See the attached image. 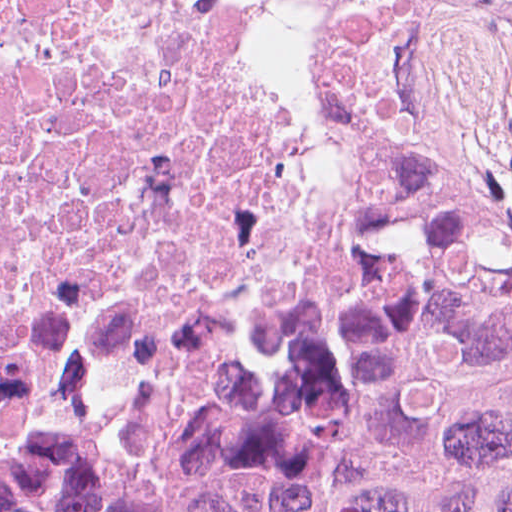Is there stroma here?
<instances>
[{
	"label": "stroma",
	"instance_id": "35a3bbf8",
	"mask_svg": "<svg viewBox=\"0 0 512 512\" xmlns=\"http://www.w3.org/2000/svg\"><path fill=\"white\" fill-rule=\"evenodd\" d=\"M363 202L364 197L361 194V212ZM350 251L339 268L337 280L342 274ZM27 474L39 477L75 494L121 502H170L208 479L196 467L179 477L150 482H124L101 477L63 476L44 473Z\"/></svg>",
	"mask_w": 512,
	"mask_h": 512
}]
</instances>
